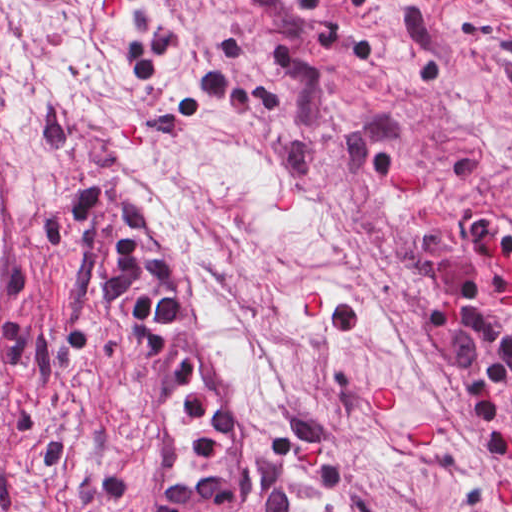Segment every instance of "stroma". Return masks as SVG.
<instances>
[{
  "mask_svg": "<svg viewBox=\"0 0 512 512\" xmlns=\"http://www.w3.org/2000/svg\"><path fill=\"white\" fill-rule=\"evenodd\" d=\"M0 98L45 156L0 512H138L74 309L119 191L208 299L242 512H512V0H0Z\"/></svg>",
  "mask_w": 512,
  "mask_h": 512,
  "instance_id": "1",
  "label": "stroma"
}]
</instances>
